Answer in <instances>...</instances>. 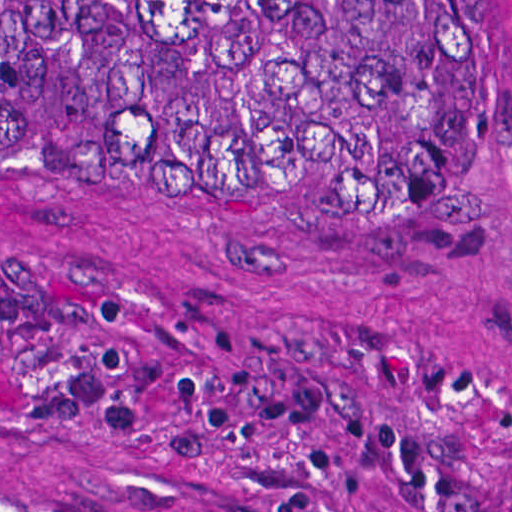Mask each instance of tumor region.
Segmentation results:
<instances>
[{"instance_id": "1", "label": "tumor region", "mask_w": 512, "mask_h": 512, "mask_svg": "<svg viewBox=\"0 0 512 512\" xmlns=\"http://www.w3.org/2000/svg\"><path fill=\"white\" fill-rule=\"evenodd\" d=\"M501 139L485 0H0V146H285L346 185ZM0 512H79L0 467Z\"/></svg>"}]
</instances>
